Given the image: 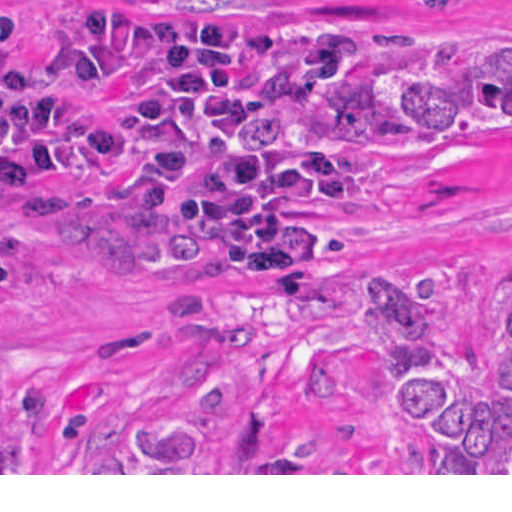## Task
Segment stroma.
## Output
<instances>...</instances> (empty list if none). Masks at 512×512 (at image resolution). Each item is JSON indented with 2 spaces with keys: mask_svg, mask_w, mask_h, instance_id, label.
Wrapping results in <instances>:
<instances>
[{
  "mask_svg": "<svg viewBox=\"0 0 512 512\" xmlns=\"http://www.w3.org/2000/svg\"><path fill=\"white\" fill-rule=\"evenodd\" d=\"M15 0L31 91L72 109L75 177L67 208L48 211L0 185V418L20 473L0 475H512V473H86L105 441L191 408L176 356L220 348L239 375L221 379L212 444L238 446L248 401L271 409L267 450L298 449L311 411L306 355L366 337V282H407L440 267L471 274L457 329L464 362L484 359L492 300L512 282V115L456 126L406 150L362 157L364 185L336 199L339 247L322 294L243 278L236 266L158 221L134 179L97 165V139L123 120L124 87L73 80L61 6ZM251 17H350L379 38L330 85L412 70H512V0L426 11L414 0H123ZM293 108V107H292ZM292 108L246 123L254 147H285Z\"/></svg>",
  "mask_w": 512,
  "mask_h": 512,
  "instance_id": "stroma-1",
  "label": "stroma"
}]
</instances>
